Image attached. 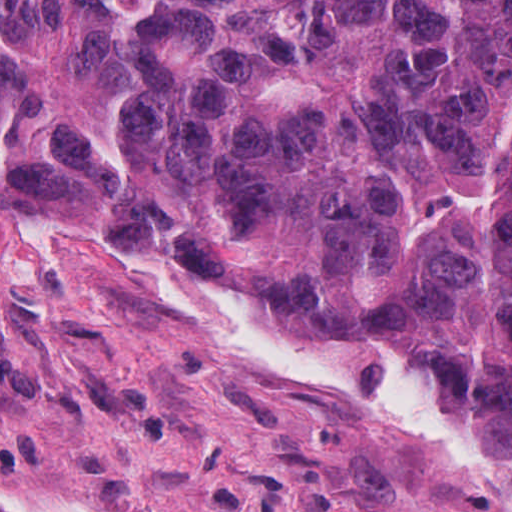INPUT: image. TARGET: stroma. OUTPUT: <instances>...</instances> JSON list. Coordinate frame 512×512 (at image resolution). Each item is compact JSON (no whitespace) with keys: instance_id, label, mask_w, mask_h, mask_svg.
Masks as SVG:
<instances>
[{"instance_id":"stroma-1","label":"stroma","mask_w":512,"mask_h":512,"mask_svg":"<svg viewBox=\"0 0 512 512\" xmlns=\"http://www.w3.org/2000/svg\"><path fill=\"white\" fill-rule=\"evenodd\" d=\"M35 219L173 267L185 238L127 246L63 178L0 186V494L72 512H512V460L266 382L89 242L7 236Z\"/></svg>"}]
</instances>
